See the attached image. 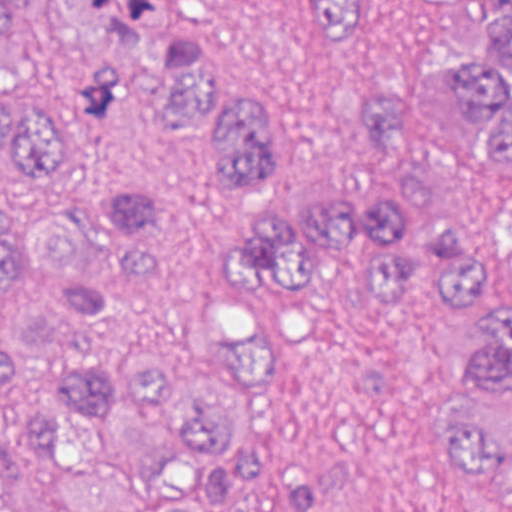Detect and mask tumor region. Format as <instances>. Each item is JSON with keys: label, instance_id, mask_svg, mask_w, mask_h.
I'll return each mask as SVG.
<instances>
[{"label": "tumor region", "instance_id": "e687c5a6", "mask_svg": "<svg viewBox=\"0 0 512 512\" xmlns=\"http://www.w3.org/2000/svg\"><path fill=\"white\" fill-rule=\"evenodd\" d=\"M38 0H0V65ZM106 53L79 105L119 109L130 72L168 81L160 121L217 135L219 191H260L272 112L217 79L201 41L157 33V0H49ZM464 7L470 0H438ZM382 0H313L310 30L347 52ZM370 132L424 147L447 167L402 170L361 197H261L235 211L217 256L226 287L292 300L340 254L367 255L370 287L416 303L430 287L477 326L466 372L487 399L455 426L453 464L512 482V0H496L476 52L409 86L361 98ZM76 168L65 129L0 90V175L46 191ZM106 218L124 251L113 285L91 270V229L0 221V288L17 266L71 286L31 320H0V512H225L227 492L262 479V441L238 395L259 369V334L203 324L189 308L190 230L153 189L117 182Z\"/></svg>", "mask_w": 512, "mask_h": 512}]
</instances>
